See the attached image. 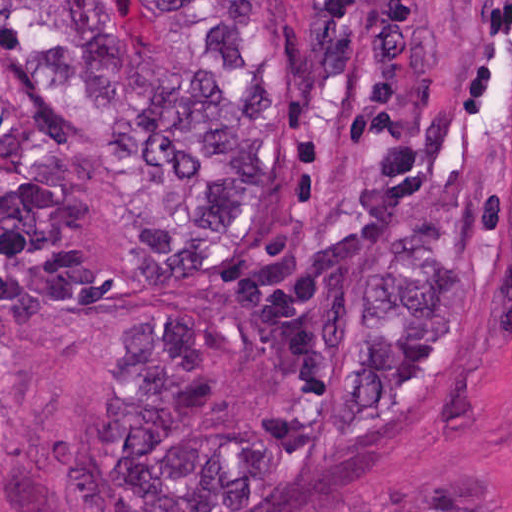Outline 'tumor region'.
Masks as SVG:
<instances>
[{
  "mask_svg": "<svg viewBox=\"0 0 512 512\" xmlns=\"http://www.w3.org/2000/svg\"><path fill=\"white\" fill-rule=\"evenodd\" d=\"M151 2L143 52L106 1H0V344L146 301L83 482L278 512L453 405L493 339L512 1Z\"/></svg>",
  "mask_w": 512,
  "mask_h": 512,
  "instance_id": "obj_1",
  "label": "tumor region"
}]
</instances>
